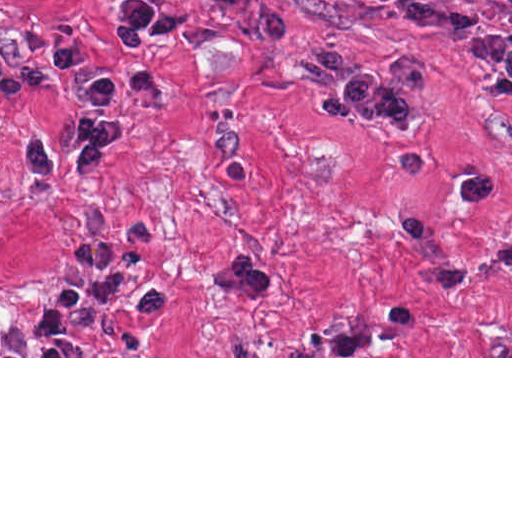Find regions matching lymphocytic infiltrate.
I'll list each match as a JSON object with an SVG mask.
<instances>
[{"mask_svg": "<svg viewBox=\"0 0 512 512\" xmlns=\"http://www.w3.org/2000/svg\"><path fill=\"white\" fill-rule=\"evenodd\" d=\"M424 36L443 41L473 61L512 80V34L471 0H359ZM176 40L186 47L206 42L184 9L157 8L139 0L120 7V41L134 65L125 72H82L84 48L67 35L56 38L58 71L72 94L84 100L75 122L74 158L59 164L42 140L23 144L22 163L39 177H80L103 166L106 152L125 133L124 123L110 114L115 96L144 105L157 92V68L151 39ZM222 296L257 298L265 277L249 257L236 252L208 275ZM171 311V293L151 284L142 271L140 250L131 244L75 243L69 272L59 279L38 308L28 347L36 356H85L82 333L104 313L154 322ZM512 313V310H511Z\"/></svg>", "mask_w": 512, "mask_h": 512, "instance_id": "f902f5d3", "label": "lymphocytic infiltrate"}]
</instances>
